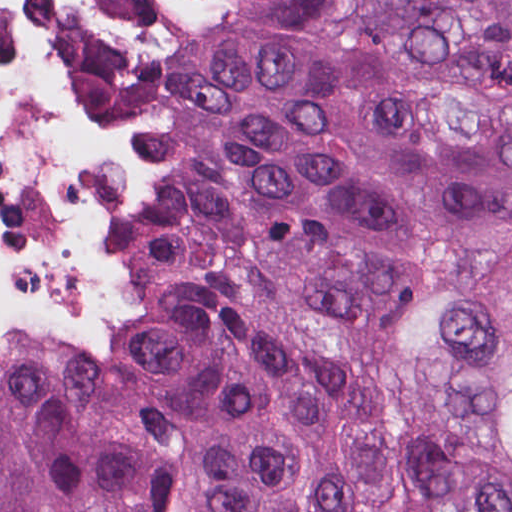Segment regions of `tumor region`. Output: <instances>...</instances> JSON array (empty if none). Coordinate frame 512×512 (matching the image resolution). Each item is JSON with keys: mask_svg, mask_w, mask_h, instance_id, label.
I'll return each instance as SVG.
<instances>
[{"mask_svg": "<svg viewBox=\"0 0 512 512\" xmlns=\"http://www.w3.org/2000/svg\"><path fill=\"white\" fill-rule=\"evenodd\" d=\"M162 289L0 344V512H512V0H123Z\"/></svg>", "mask_w": 512, "mask_h": 512, "instance_id": "tumor-region-1", "label": "tumor region"}]
</instances>
